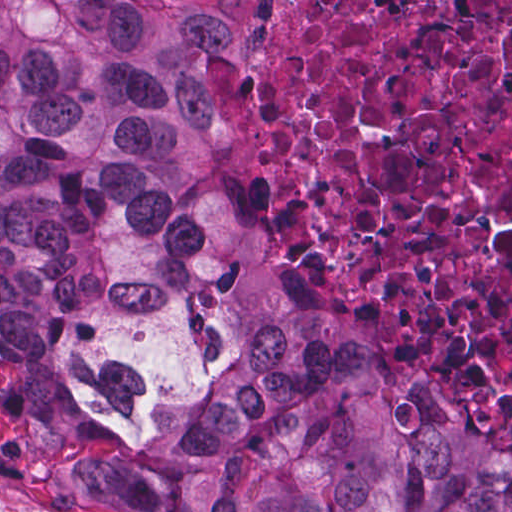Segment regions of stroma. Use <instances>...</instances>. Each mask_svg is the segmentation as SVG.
Returning a JSON list of instances; mask_svg holds the SVG:
<instances>
[{
	"label": "stroma",
	"instance_id": "1",
	"mask_svg": "<svg viewBox=\"0 0 512 512\" xmlns=\"http://www.w3.org/2000/svg\"><path fill=\"white\" fill-rule=\"evenodd\" d=\"M271 0H248V43L234 56L199 60V83L212 109L206 144V167L216 183L251 196L266 212L282 220L308 252L337 280L341 299L357 332L373 347L391 382L403 391L438 393L464 408L500 436L512 442V420L481 405L468 387H427L398 365L384 346L370 337L360 316L355 292L344 280L326 245L290 210L271 199L245 178L221 172V126L213 91V68H238L254 51L261 35V13ZM30 407L27 391L14 381H0V438L27 429ZM0 512H112L79 474H38L0 463Z\"/></svg>",
	"mask_w": 512,
	"mask_h": 512
}]
</instances>
